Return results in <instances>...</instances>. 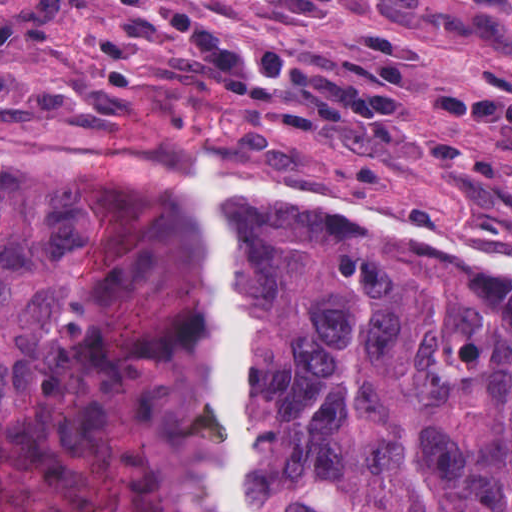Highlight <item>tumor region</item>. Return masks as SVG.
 I'll use <instances>...</instances> for the list:
<instances>
[{"label": "tumor region", "mask_w": 512, "mask_h": 512, "mask_svg": "<svg viewBox=\"0 0 512 512\" xmlns=\"http://www.w3.org/2000/svg\"><path fill=\"white\" fill-rule=\"evenodd\" d=\"M195 177L0 151V512H220ZM222 184L251 512H512V273Z\"/></svg>", "instance_id": "obj_1"}]
</instances>
